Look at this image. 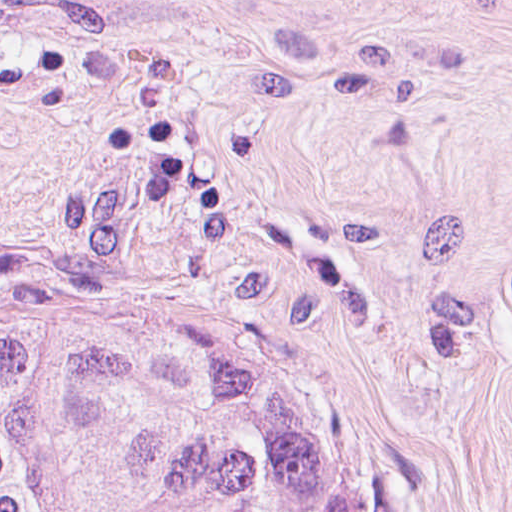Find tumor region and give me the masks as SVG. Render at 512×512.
I'll return each mask as SVG.
<instances>
[{"instance_id":"obj_1","label":"tumor region","mask_w":512,"mask_h":512,"mask_svg":"<svg viewBox=\"0 0 512 512\" xmlns=\"http://www.w3.org/2000/svg\"><path fill=\"white\" fill-rule=\"evenodd\" d=\"M0 512H406L313 331L192 293L0 326Z\"/></svg>"}]
</instances>
